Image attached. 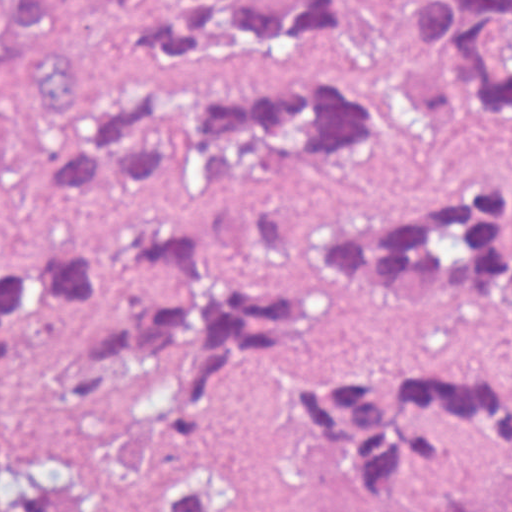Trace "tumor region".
<instances>
[{
  "instance_id": "e687c5a6",
  "label": "tumor region",
  "mask_w": 512,
  "mask_h": 512,
  "mask_svg": "<svg viewBox=\"0 0 512 512\" xmlns=\"http://www.w3.org/2000/svg\"><path fill=\"white\" fill-rule=\"evenodd\" d=\"M37 190L75 207L236 178H316L360 146L512 128V0H0ZM308 259L399 300L478 292L512 311L503 185L439 181L343 205ZM73 320L54 388L77 455L151 512H235L205 467L100 439L109 394L266 405L343 498L383 511L484 450L512 474V376L327 372L279 361L308 288L177 224L0 251V364ZM0 512H47L0 440ZM512 512V490L478 511Z\"/></svg>"
}]
</instances>
